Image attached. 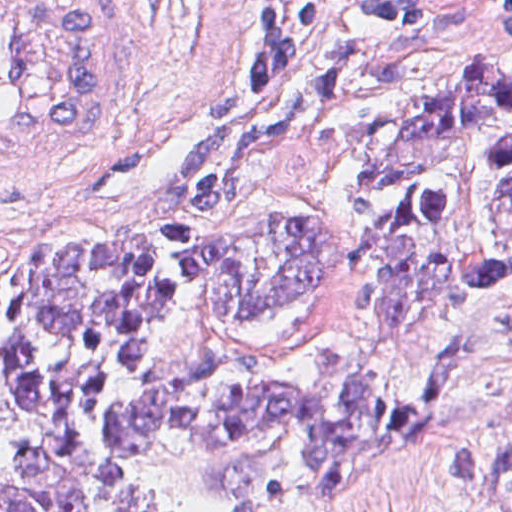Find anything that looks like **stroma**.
I'll list each match as a JSON object with an SVG mask.
<instances>
[{
    "label": "stroma",
    "mask_w": 512,
    "mask_h": 512,
    "mask_svg": "<svg viewBox=\"0 0 512 512\" xmlns=\"http://www.w3.org/2000/svg\"><path fill=\"white\" fill-rule=\"evenodd\" d=\"M141 1V94L127 121L49 183L0 190V262L31 265L45 237L73 243H144L161 236L154 219L161 185L185 145L234 119L280 107L303 86L359 55L485 61L512 78V0H0ZM267 1H431L421 21L396 29H342L324 36L271 89L251 90L236 67L243 35ZM404 34V35H403ZM403 35V36H402ZM353 163L330 145L289 140L255 163L250 198L215 219L218 236L238 225L320 215L348 236L336 293L285 306L246 323L239 347H259L287 376L306 375L319 347L354 352L376 391L427 409L429 440L393 455L341 487L297 496L271 512H484L464 479L455 437L424 394L415 362L438 336L476 315L512 279L460 299L433 325L391 339L361 332L353 317L367 273L352 240ZM25 418L0 359V467L24 439Z\"/></svg>",
    "instance_id": "35a3bbf8"
}]
</instances>
